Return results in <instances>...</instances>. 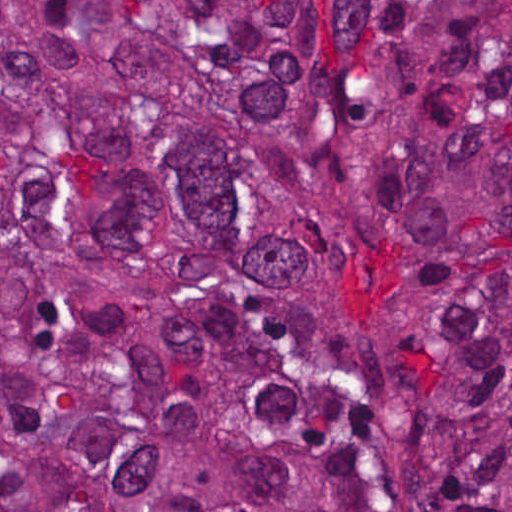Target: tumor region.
<instances>
[{"mask_svg": "<svg viewBox=\"0 0 512 512\" xmlns=\"http://www.w3.org/2000/svg\"><path fill=\"white\" fill-rule=\"evenodd\" d=\"M0 512H512V0H0Z\"/></svg>", "mask_w": 512, "mask_h": 512, "instance_id": "e687c5a6", "label": "tumor region"}]
</instances>
